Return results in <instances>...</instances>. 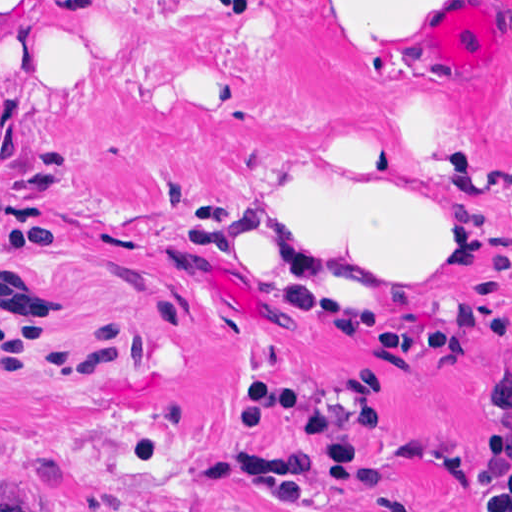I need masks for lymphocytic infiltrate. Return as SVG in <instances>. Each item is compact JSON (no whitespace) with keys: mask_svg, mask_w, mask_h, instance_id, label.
Returning a JSON list of instances; mask_svg holds the SVG:
<instances>
[{"mask_svg":"<svg viewBox=\"0 0 512 512\" xmlns=\"http://www.w3.org/2000/svg\"><path fill=\"white\" fill-rule=\"evenodd\" d=\"M371 338L379 354L395 364L430 361L458 354L480 340L493 348L512 350V308L476 295L465 303L456 321L434 328L416 319H379ZM512 406V383L498 393ZM276 418H297L308 426L307 446L284 456L230 454L214 462L204 482L249 489L291 508H307L321 469L333 487L377 489L379 472L363 456V440L386 418L367 423L348 419L321 406L297 388L252 385L246 398L245 420L263 427ZM482 443L479 485L487 499L482 512H512V428L500 419L484 421L469 434ZM380 512H418L409 504L383 498Z\"/></svg>","mask_w":512,"mask_h":512,"instance_id":"1","label":"lymphocytic infiltrate"}]
</instances>
